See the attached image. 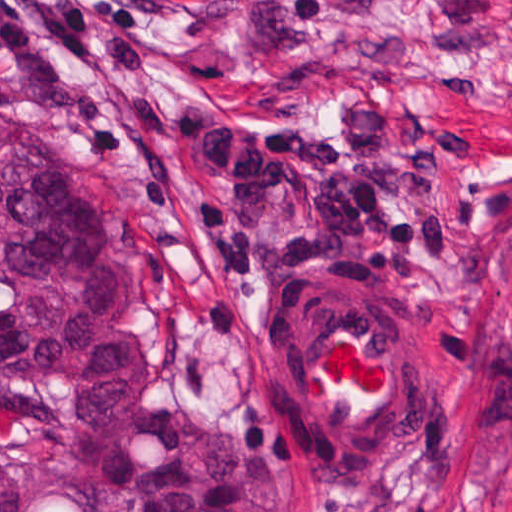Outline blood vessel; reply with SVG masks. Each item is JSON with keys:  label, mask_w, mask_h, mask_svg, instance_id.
Segmentation results:
<instances>
[{"label": "blood vessel", "mask_w": 512, "mask_h": 512, "mask_svg": "<svg viewBox=\"0 0 512 512\" xmlns=\"http://www.w3.org/2000/svg\"><path fill=\"white\" fill-rule=\"evenodd\" d=\"M262 362L306 475L366 485L402 450L420 362L381 293L347 278L301 280L268 322Z\"/></svg>", "instance_id": "blood-vessel-1"}]
</instances>
